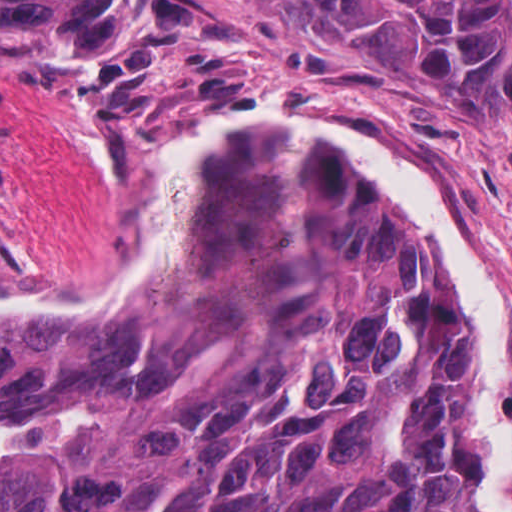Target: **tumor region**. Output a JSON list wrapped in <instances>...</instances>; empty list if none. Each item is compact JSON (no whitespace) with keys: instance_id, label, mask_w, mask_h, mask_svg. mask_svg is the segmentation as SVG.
Returning <instances> with one entry per match:
<instances>
[{"instance_id":"1","label":"tumor region","mask_w":512,"mask_h":512,"mask_svg":"<svg viewBox=\"0 0 512 512\" xmlns=\"http://www.w3.org/2000/svg\"><path fill=\"white\" fill-rule=\"evenodd\" d=\"M385 45L415 103L512 106V0H285ZM155 49L142 0H0V57ZM473 324L432 251L314 145L243 135L121 321H0V512H481Z\"/></svg>"}]
</instances>
